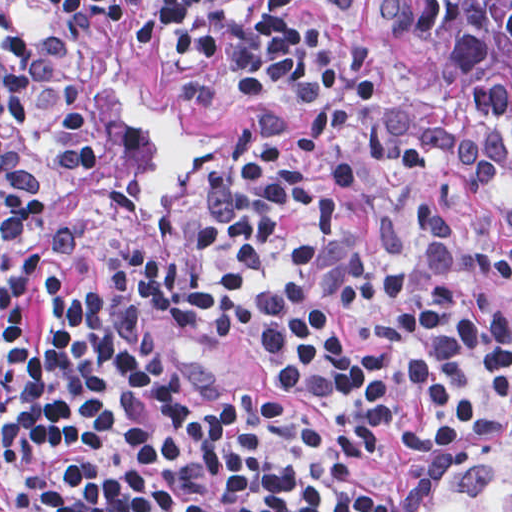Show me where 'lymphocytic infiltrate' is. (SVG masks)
<instances>
[{"label":"lymphocytic infiltrate","instance_id":"1","mask_svg":"<svg viewBox=\"0 0 512 512\" xmlns=\"http://www.w3.org/2000/svg\"><path fill=\"white\" fill-rule=\"evenodd\" d=\"M125 0H1L2 164L20 34L59 20L115 47ZM219 52L258 109L168 242L171 321L341 405L314 430L269 399L195 396L116 299L43 283L1 247V512H413L424 471L487 436L512 357V249L413 200L399 256L365 246L340 197L433 168L428 111L373 77L355 0H155L142 44ZM462 182L498 179L464 152ZM503 220L512 231V188Z\"/></svg>","mask_w":512,"mask_h":512}]
</instances>
